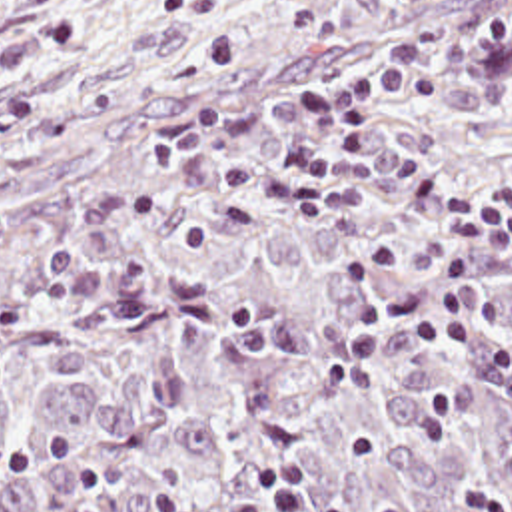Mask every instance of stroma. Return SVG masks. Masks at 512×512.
I'll return each mask as SVG.
<instances>
[{
  "label": "stroma",
  "mask_w": 512,
  "mask_h": 512,
  "mask_svg": "<svg viewBox=\"0 0 512 512\" xmlns=\"http://www.w3.org/2000/svg\"><path fill=\"white\" fill-rule=\"evenodd\" d=\"M234 0H0V69L194 41L222 27Z\"/></svg>",
  "instance_id": "stroma-1"
}]
</instances>
